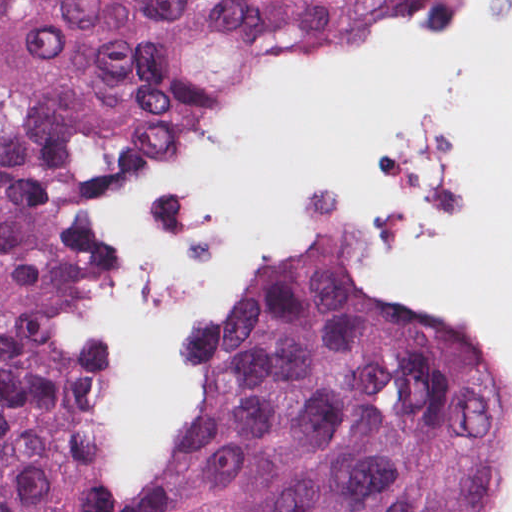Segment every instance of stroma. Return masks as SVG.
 <instances>
[{
    "label": "stroma",
    "mask_w": 512,
    "mask_h": 512,
    "mask_svg": "<svg viewBox=\"0 0 512 512\" xmlns=\"http://www.w3.org/2000/svg\"><path fill=\"white\" fill-rule=\"evenodd\" d=\"M509 0H422L405 31L362 48L316 76L238 110L114 189L82 206L63 251L110 362V512H135L130 484L153 464L165 397L177 376L223 328L250 291L321 253L346 261L369 298L412 323L450 329L508 375L512 426V322L407 271L402 236L474 223L484 209L481 133L444 102H399L382 128L378 165L330 172L301 196L296 225L221 266L173 309L164 389L140 385L125 245L145 210L216 169L305 83L345 67L403 64L455 51L500 30Z\"/></svg>",
    "instance_id": "35a3bbf8"
}]
</instances>
